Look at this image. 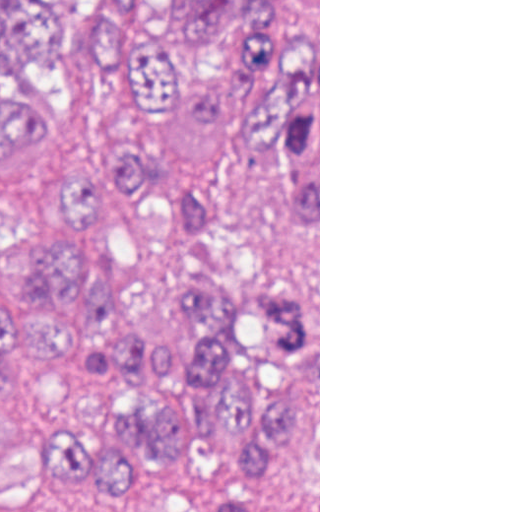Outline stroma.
Here are the masks:
<instances>
[{
  "label": "stroma",
  "mask_w": 512,
  "mask_h": 512,
  "mask_svg": "<svg viewBox=\"0 0 512 512\" xmlns=\"http://www.w3.org/2000/svg\"><path fill=\"white\" fill-rule=\"evenodd\" d=\"M156 146L167 171L213 194L216 243L187 230L153 192L130 189L81 220L90 267L117 286L129 321L166 346L185 338L175 310V277L185 260L246 280H283L308 296L302 420L276 471V493L281 512H320V0L318 160L257 149L231 112L214 132H197L173 108L161 112ZM250 455L244 437L215 427L198 453L152 465L129 491L97 478L67 488L0 482V512H213L221 487L247 470Z\"/></svg>",
  "instance_id": "1"
}]
</instances>
